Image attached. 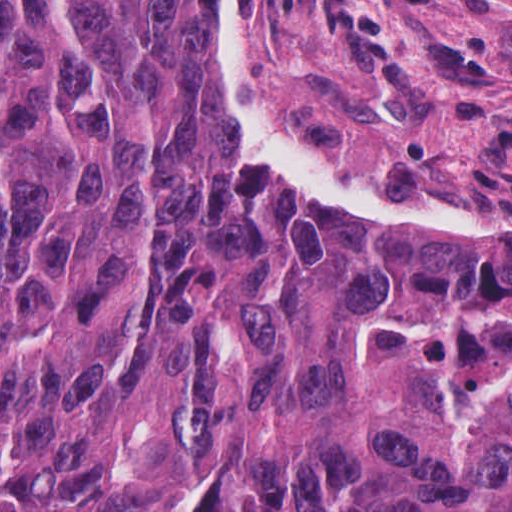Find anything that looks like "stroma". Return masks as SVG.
Wrapping results in <instances>:
<instances>
[{
    "instance_id": "1",
    "label": "stroma",
    "mask_w": 512,
    "mask_h": 512,
    "mask_svg": "<svg viewBox=\"0 0 512 512\" xmlns=\"http://www.w3.org/2000/svg\"><path fill=\"white\" fill-rule=\"evenodd\" d=\"M213 65L288 184L512 245V0H223Z\"/></svg>"
}]
</instances>
